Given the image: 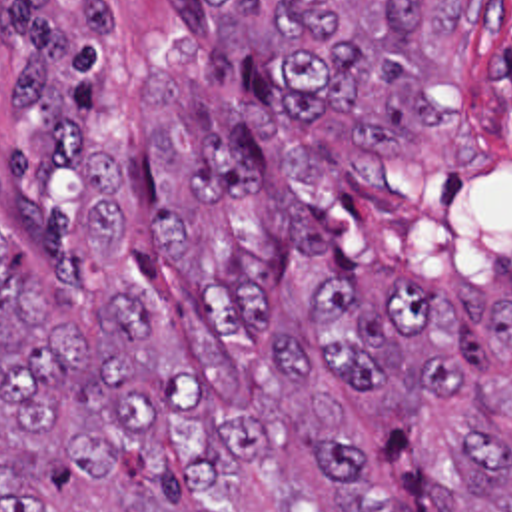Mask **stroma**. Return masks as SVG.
Wrapping results in <instances>:
<instances>
[{
  "label": "stroma",
  "mask_w": 512,
  "mask_h": 512,
  "mask_svg": "<svg viewBox=\"0 0 512 512\" xmlns=\"http://www.w3.org/2000/svg\"><path fill=\"white\" fill-rule=\"evenodd\" d=\"M20 3L0 0V235L16 253L2 85ZM68 3L92 51L106 57L142 51L186 21L202 25L194 0ZM418 103L434 127L402 145H356L342 123L356 177L354 269H388L408 287L438 291L465 283L487 304L512 308V0H493L489 41L475 33L439 51ZM312 380L342 410L346 446L360 452L390 498L404 512H438L432 482L461 478L453 442L473 420L467 398L404 382L366 388L322 366ZM22 494H38L48 512H170V496L142 452L122 448L114 480L94 482L0 404V498Z\"/></svg>",
  "instance_id": "1"
}]
</instances>
